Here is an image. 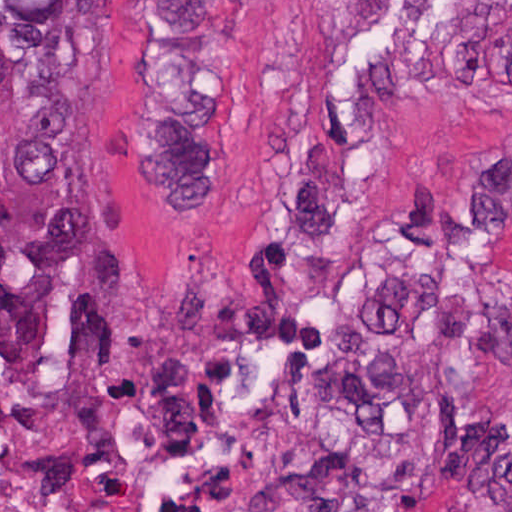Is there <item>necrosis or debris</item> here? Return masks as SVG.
<instances>
[{
    "label": "necrosis or debris",
    "mask_w": 512,
    "mask_h": 512,
    "mask_svg": "<svg viewBox=\"0 0 512 512\" xmlns=\"http://www.w3.org/2000/svg\"><path fill=\"white\" fill-rule=\"evenodd\" d=\"M0 512H66L27 483L0 481Z\"/></svg>",
    "instance_id": "obj_1"
}]
</instances>
